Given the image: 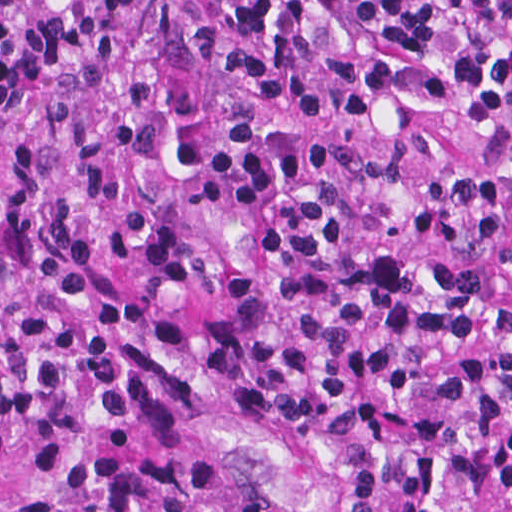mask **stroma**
Segmentation results:
<instances>
[{
  "label": "stroma",
  "instance_id": "stroma-1",
  "mask_svg": "<svg viewBox=\"0 0 512 512\" xmlns=\"http://www.w3.org/2000/svg\"><path fill=\"white\" fill-rule=\"evenodd\" d=\"M223 0H136L147 24L63 56L28 95L0 105V179L21 134L106 130L128 118L163 110L193 88H220L227 70L214 55L189 59L196 28ZM204 427L273 435L287 453L307 512H354L345 471L280 424L231 406L170 412L153 423L104 440L29 436L0 449V512H36L79 488L124 473L131 453L161 451Z\"/></svg>",
  "mask_w": 512,
  "mask_h": 512
}]
</instances>
